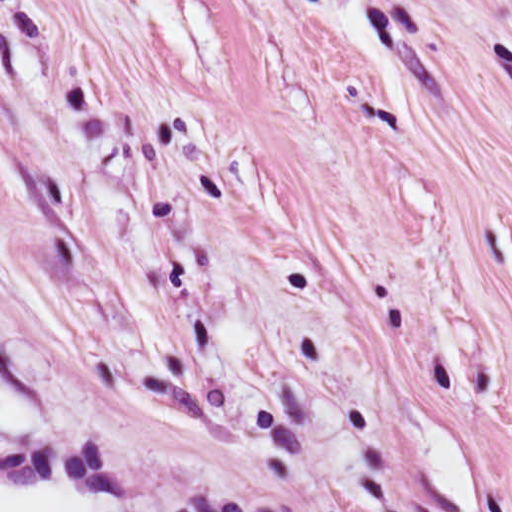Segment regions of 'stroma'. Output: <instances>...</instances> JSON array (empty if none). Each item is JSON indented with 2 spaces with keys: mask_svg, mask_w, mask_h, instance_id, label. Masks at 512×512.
<instances>
[{
  "mask_svg": "<svg viewBox=\"0 0 512 512\" xmlns=\"http://www.w3.org/2000/svg\"><path fill=\"white\" fill-rule=\"evenodd\" d=\"M93 512H512V0H0V482Z\"/></svg>",
  "mask_w": 512,
  "mask_h": 512,
  "instance_id": "stroma-1",
  "label": "stroma"
}]
</instances>
